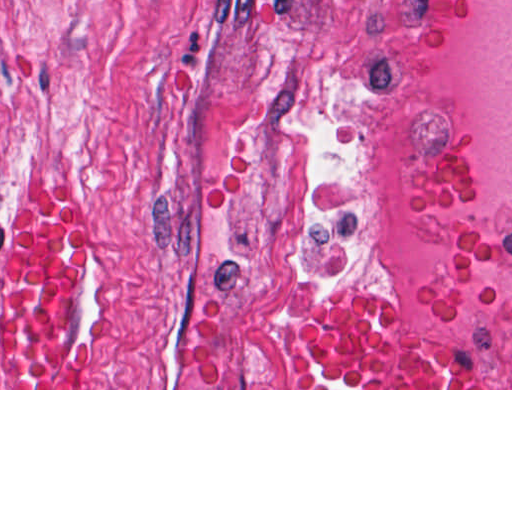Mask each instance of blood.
<instances>
[{
    "instance_id": "obj_1",
    "label": "blood",
    "mask_w": 512,
    "mask_h": 512,
    "mask_svg": "<svg viewBox=\"0 0 512 512\" xmlns=\"http://www.w3.org/2000/svg\"><path fill=\"white\" fill-rule=\"evenodd\" d=\"M80 204L45 191L18 222L5 261L0 388H80L64 343L61 281ZM292 349L317 388H438L410 352L385 298L343 288L296 330Z\"/></svg>"
}]
</instances>
